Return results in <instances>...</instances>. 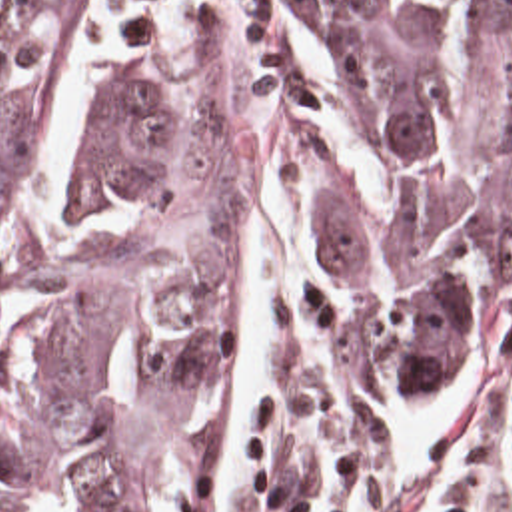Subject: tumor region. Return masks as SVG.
Wrapping results in <instances>:
<instances>
[{
    "label": "tumor region",
    "mask_w": 512,
    "mask_h": 512,
    "mask_svg": "<svg viewBox=\"0 0 512 512\" xmlns=\"http://www.w3.org/2000/svg\"><path fill=\"white\" fill-rule=\"evenodd\" d=\"M267 5L357 356L375 390H443L481 364L512 279V0ZM79 23L77 0H1L0 512H25L45 472L67 474L73 512H181L231 289V139L121 59L81 191L141 195L159 227L19 265L15 145Z\"/></svg>",
    "instance_id": "tumor-region-1"
}]
</instances>
